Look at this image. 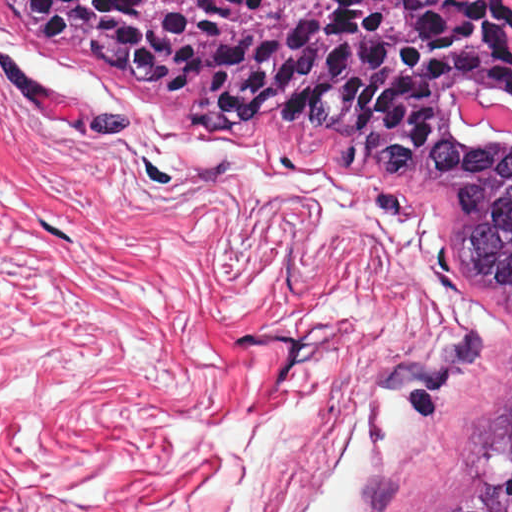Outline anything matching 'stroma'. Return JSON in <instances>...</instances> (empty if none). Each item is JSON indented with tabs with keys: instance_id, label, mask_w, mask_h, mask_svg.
Returning <instances> with one entry per match:
<instances>
[{
	"instance_id": "35a3bbf8",
	"label": "stroma",
	"mask_w": 512,
	"mask_h": 512,
	"mask_svg": "<svg viewBox=\"0 0 512 512\" xmlns=\"http://www.w3.org/2000/svg\"><path fill=\"white\" fill-rule=\"evenodd\" d=\"M131 95L0 16V512H223V426L268 423L258 512H412L500 351L408 415L402 375L471 328L433 227L166 111L81 126Z\"/></svg>"
}]
</instances>
